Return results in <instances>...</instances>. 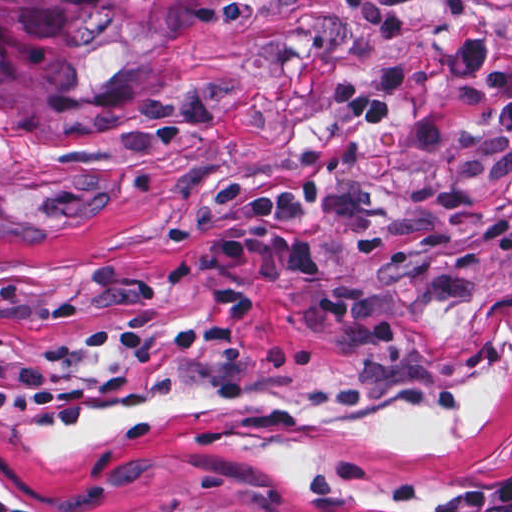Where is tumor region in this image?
Masks as SVG:
<instances>
[{"instance_id": "1", "label": "tumor region", "mask_w": 512, "mask_h": 512, "mask_svg": "<svg viewBox=\"0 0 512 512\" xmlns=\"http://www.w3.org/2000/svg\"><path fill=\"white\" fill-rule=\"evenodd\" d=\"M299 0H1V114L29 130H107L149 108L216 23Z\"/></svg>"}]
</instances>
